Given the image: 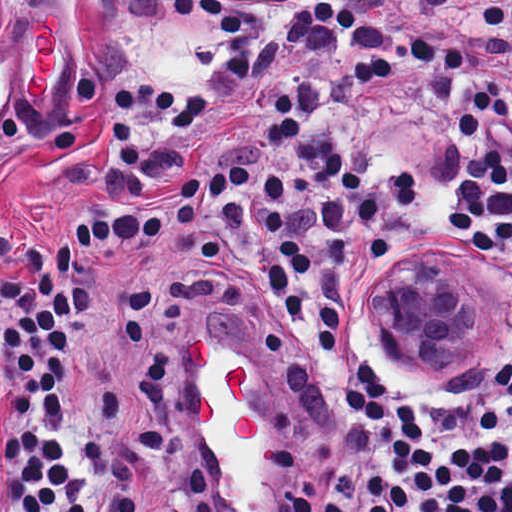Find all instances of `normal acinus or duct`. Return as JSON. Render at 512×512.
<instances>
[{"instance_id":"normal-acinus-or-duct-1","label":"normal acinus or duct","mask_w":512,"mask_h":512,"mask_svg":"<svg viewBox=\"0 0 512 512\" xmlns=\"http://www.w3.org/2000/svg\"><path fill=\"white\" fill-rule=\"evenodd\" d=\"M380 314L403 365L435 379L484 354L492 309L456 269L417 264L385 286Z\"/></svg>"}]
</instances>
